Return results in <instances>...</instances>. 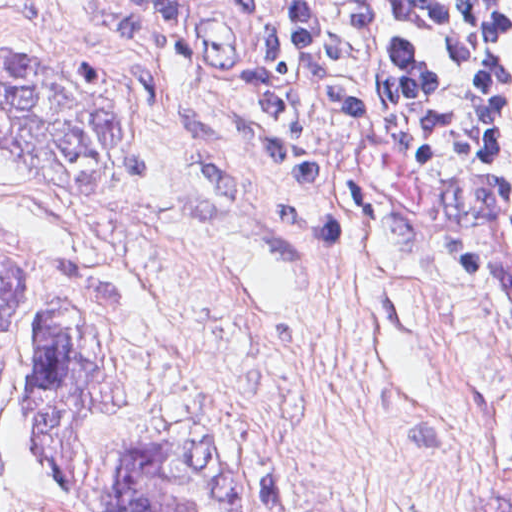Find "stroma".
<instances>
[{
	"label": "stroma",
	"instance_id": "35a3bbf8",
	"mask_svg": "<svg viewBox=\"0 0 512 512\" xmlns=\"http://www.w3.org/2000/svg\"><path fill=\"white\" fill-rule=\"evenodd\" d=\"M170 63L126 0H0V51L123 75L144 180L69 196L0 147V241L100 251L138 288L116 332L130 406L72 421L86 463L165 423L219 421L259 512H512V235L449 156L289 56L248 0H177ZM251 60L330 142L333 188L233 158ZM0 512H70L26 409Z\"/></svg>",
	"mask_w": 512,
	"mask_h": 512
}]
</instances>
